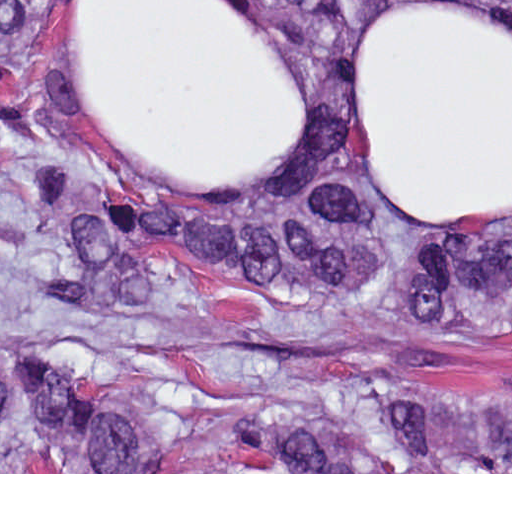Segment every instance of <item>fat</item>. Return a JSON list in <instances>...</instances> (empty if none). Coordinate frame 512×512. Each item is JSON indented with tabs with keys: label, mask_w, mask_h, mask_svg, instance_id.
<instances>
[{
	"label": "fat",
	"mask_w": 512,
	"mask_h": 512,
	"mask_svg": "<svg viewBox=\"0 0 512 512\" xmlns=\"http://www.w3.org/2000/svg\"><path fill=\"white\" fill-rule=\"evenodd\" d=\"M378 12L352 49L363 153L404 212L512 206V23L451 0ZM72 102L132 170L241 193L304 136V88L236 0H79Z\"/></svg>",
	"instance_id": "53f6f03d"
}]
</instances>
